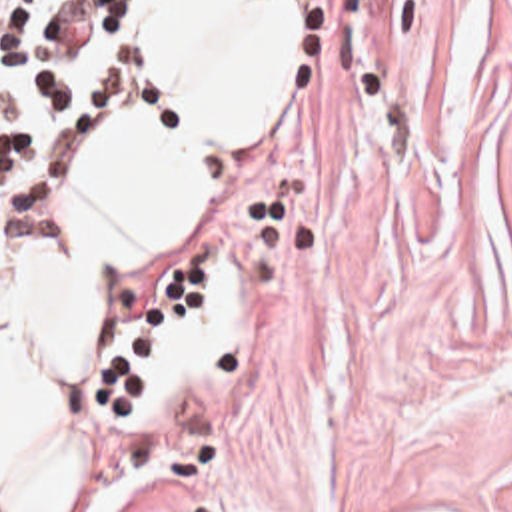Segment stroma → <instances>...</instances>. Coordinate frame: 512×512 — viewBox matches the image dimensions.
<instances>
[{
    "label": "stroma",
    "mask_w": 512,
    "mask_h": 512,
    "mask_svg": "<svg viewBox=\"0 0 512 512\" xmlns=\"http://www.w3.org/2000/svg\"><path fill=\"white\" fill-rule=\"evenodd\" d=\"M228 254L218 370L138 436L152 386L114 336L194 314ZM80 412L118 512H512V0H304L290 112L180 254L114 286Z\"/></svg>",
    "instance_id": "1"
}]
</instances>
